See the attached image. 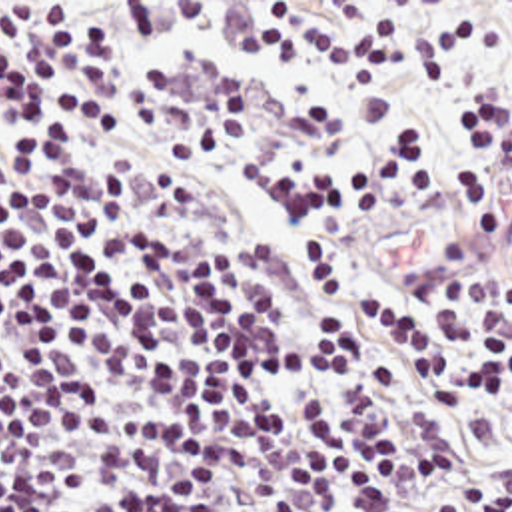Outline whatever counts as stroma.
<instances>
[{"label": "stroma", "mask_w": 512, "mask_h": 512, "mask_svg": "<svg viewBox=\"0 0 512 512\" xmlns=\"http://www.w3.org/2000/svg\"><path fill=\"white\" fill-rule=\"evenodd\" d=\"M498 146L512 164V138L498 140ZM428 150L436 158L454 160L460 154V144L432 146ZM362 156L370 154L336 156V160ZM203 174L259 232L295 250V232L287 220L267 212L253 198L249 190V166L203 170ZM484 218L486 214H448L418 224L390 218H354L344 224L340 234V264L336 275L408 268L432 250L476 232Z\"/></svg>", "instance_id": "obj_1"}]
</instances>
